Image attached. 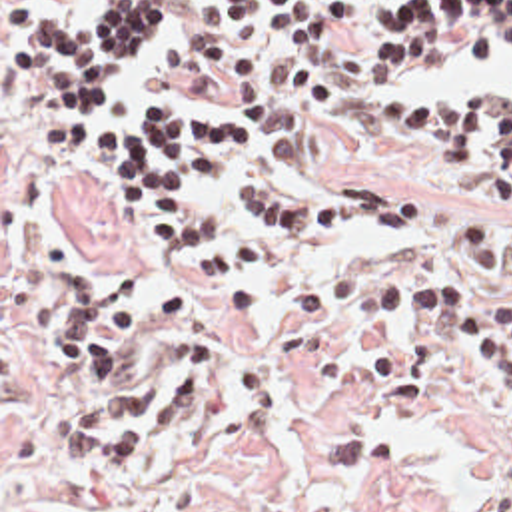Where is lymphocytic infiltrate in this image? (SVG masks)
<instances>
[{
  "label": "lymphocytic infiltrate",
  "instance_id": "lymphocytic-infiltrate-1",
  "mask_svg": "<svg viewBox=\"0 0 512 512\" xmlns=\"http://www.w3.org/2000/svg\"><path fill=\"white\" fill-rule=\"evenodd\" d=\"M238 24L268 20L294 50H335L341 28L363 16L347 0H214ZM176 20V0H100L78 24L22 18L12 28V80L42 94L48 138L80 150L86 174L150 232L184 240L178 273L214 313H240L258 297L264 257L256 240L234 234L204 210L210 190L260 222L339 240H371L413 222V204L351 186H297L270 178V142L244 118L178 102L112 110L136 84L144 50ZM381 48L367 64L373 84H417L429 64L477 58L512 38V2L395 0L377 12ZM399 66L381 76L377 66ZM417 156L453 184L512 208V90L509 94H401L389 116ZM407 122L419 132L411 134ZM465 265L459 273L371 279L345 265L297 277L301 323L335 329L421 323L469 359L493 367L512 395V236L487 210L449 226ZM196 244V257L190 244ZM28 279L46 295V347L66 375L86 379L94 403L72 413L62 457L70 473L134 469L164 445V423L202 409L220 357L216 337L180 341L144 369L134 365L140 329L168 325L186 305L174 281L136 305L122 297L136 265L82 283L74 257L28 252ZM485 512H512V431L489 485Z\"/></svg>",
  "mask_w": 512,
  "mask_h": 512
}]
</instances>
